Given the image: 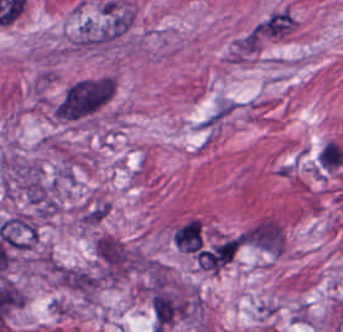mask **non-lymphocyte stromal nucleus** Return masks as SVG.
<instances>
[{
	"mask_svg": "<svg viewBox=\"0 0 343 332\" xmlns=\"http://www.w3.org/2000/svg\"><path fill=\"white\" fill-rule=\"evenodd\" d=\"M241 246L265 255L278 256L283 251L284 233L281 223L261 216L239 233Z\"/></svg>",
	"mask_w": 343,
	"mask_h": 332,
	"instance_id": "non-lymphocyte-stromal-nucleus-1",
	"label": "non-lymphocyte stromal nucleus"
},
{
	"mask_svg": "<svg viewBox=\"0 0 343 332\" xmlns=\"http://www.w3.org/2000/svg\"><path fill=\"white\" fill-rule=\"evenodd\" d=\"M151 308L153 322L162 330L185 313V303L172 291L160 288L151 299Z\"/></svg>",
	"mask_w": 343,
	"mask_h": 332,
	"instance_id": "non-lymphocyte-stromal-nucleus-2",
	"label": "non-lymphocyte stromal nucleus"
},
{
	"mask_svg": "<svg viewBox=\"0 0 343 332\" xmlns=\"http://www.w3.org/2000/svg\"><path fill=\"white\" fill-rule=\"evenodd\" d=\"M173 240L185 252H195L201 245L200 220L190 219L177 229Z\"/></svg>",
	"mask_w": 343,
	"mask_h": 332,
	"instance_id": "non-lymphocyte-stromal-nucleus-3",
	"label": "non-lymphocyte stromal nucleus"
},
{
	"mask_svg": "<svg viewBox=\"0 0 343 332\" xmlns=\"http://www.w3.org/2000/svg\"><path fill=\"white\" fill-rule=\"evenodd\" d=\"M234 106L229 99H221L199 121L200 129H209L224 120L233 110Z\"/></svg>",
	"mask_w": 343,
	"mask_h": 332,
	"instance_id": "non-lymphocyte-stromal-nucleus-4",
	"label": "non-lymphocyte stromal nucleus"
},
{
	"mask_svg": "<svg viewBox=\"0 0 343 332\" xmlns=\"http://www.w3.org/2000/svg\"><path fill=\"white\" fill-rule=\"evenodd\" d=\"M317 160L320 168L329 172L340 166L343 161V151L334 142L328 141L322 146Z\"/></svg>",
	"mask_w": 343,
	"mask_h": 332,
	"instance_id": "non-lymphocyte-stromal-nucleus-5",
	"label": "non-lymphocyte stromal nucleus"
}]
</instances>
